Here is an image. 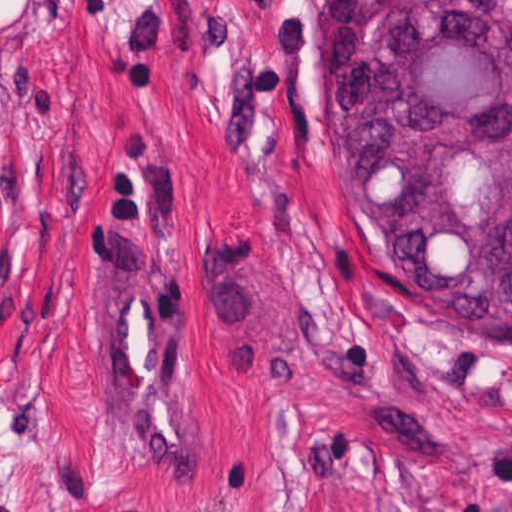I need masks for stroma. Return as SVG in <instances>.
<instances>
[{
	"instance_id": "stroma-1",
	"label": "stroma",
	"mask_w": 512,
	"mask_h": 512,
	"mask_svg": "<svg viewBox=\"0 0 512 512\" xmlns=\"http://www.w3.org/2000/svg\"><path fill=\"white\" fill-rule=\"evenodd\" d=\"M334 0H0V512H512V346L424 315L349 187ZM358 203L373 227L350 53ZM149 212L203 447L115 454L102 328Z\"/></svg>"
}]
</instances>
